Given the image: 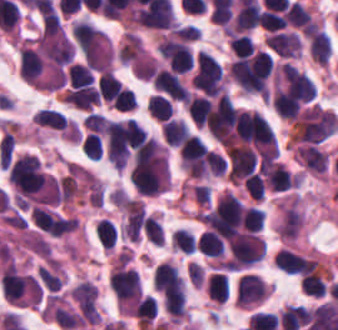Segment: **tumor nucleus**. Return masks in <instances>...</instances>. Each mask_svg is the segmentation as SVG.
Here are the masks:
<instances>
[{"mask_svg": "<svg viewBox=\"0 0 338 330\" xmlns=\"http://www.w3.org/2000/svg\"><path fill=\"white\" fill-rule=\"evenodd\" d=\"M269 49L282 58H298L300 53L299 37L290 32H270L264 39Z\"/></svg>", "mask_w": 338, "mask_h": 330, "instance_id": "tumor-nucleus-1", "label": "tumor nucleus"}]
</instances>
